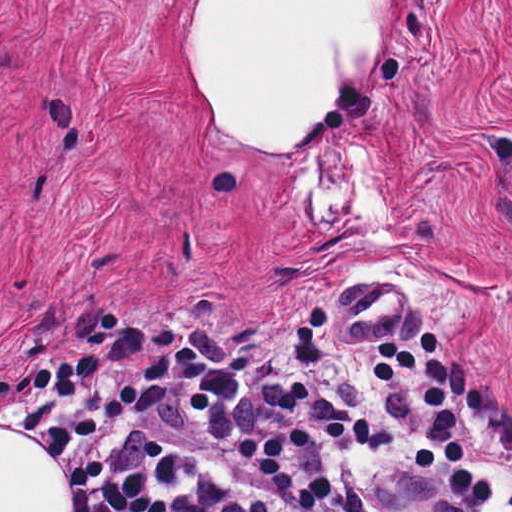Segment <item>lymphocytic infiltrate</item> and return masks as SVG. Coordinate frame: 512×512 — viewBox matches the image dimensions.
I'll return each mask as SVG.
<instances>
[{
  "label": "lymphocytic infiltrate",
  "mask_w": 512,
  "mask_h": 512,
  "mask_svg": "<svg viewBox=\"0 0 512 512\" xmlns=\"http://www.w3.org/2000/svg\"><path fill=\"white\" fill-rule=\"evenodd\" d=\"M103 356L69 363L29 366L0 375V428L20 431L38 443L63 486V512H273L281 499L299 512L323 507L333 499L331 478L296 486L290 465L295 455L315 443H349L359 448L391 441L383 431L393 418L394 391L410 373H421L426 420L413 446L421 471L446 463L463 498L481 504L494 484L471 471L458 439L459 422L447 403L445 359L431 331L412 352L398 340L375 347L372 369L382 408L371 421L340 412L306 381L289 385L276 410L292 417L284 431L243 438L230 455L253 468L263 490L225 493L214 480L201 481L181 468L165 445L138 441L116 425L133 416L156 412L207 375L203 357L188 345L158 356L115 393L97 412L78 403L79 395L102 377ZM148 447L177 465L168 481L159 459L142 460ZM204 483L219 493L197 489ZM512 512V497L510 499Z\"/></svg>",
  "instance_id": "f902f5d3"
}]
</instances>
